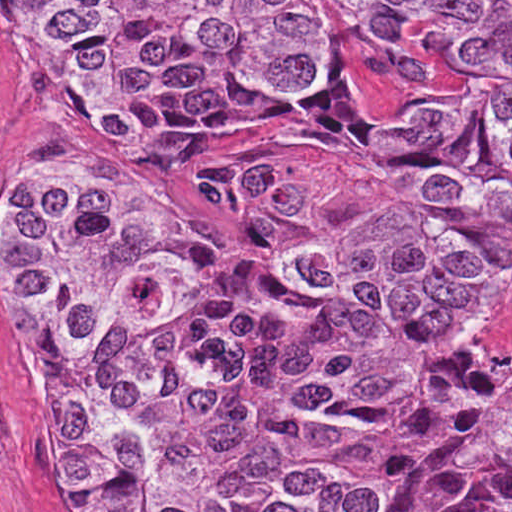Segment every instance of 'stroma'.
Listing matches in <instances>:
<instances>
[{
  "label": "stroma",
  "instance_id": "stroma-1",
  "mask_svg": "<svg viewBox=\"0 0 512 512\" xmlns=\"http://www.w3.org/2000/svg\"><path fill=\"white\" fill-rule=\"evenodd\" d=\"M23 1H306L311 82L293 99L225 132L164 138L118 130L84 112L36 37ZM371 1L512 0H0V203L20 169L46 163L138 180L190 204L220 229L260 253L202 192V171L224 160L283 166L317 180L323 196L299 222L289 258H316L394 214H417L466 227L350 153L327 144L281 113L342 61L371 112L407 122L451 96L471 92L512 50H460L390 18ZM432 362L478 377L512 375V286L480 324L432 344ZM0 512H54L32 459L23 410L20 324L0 296Z\"/></svg>",
  "mask_w": 512,
  "mask_h": 512
}]
</instances>
